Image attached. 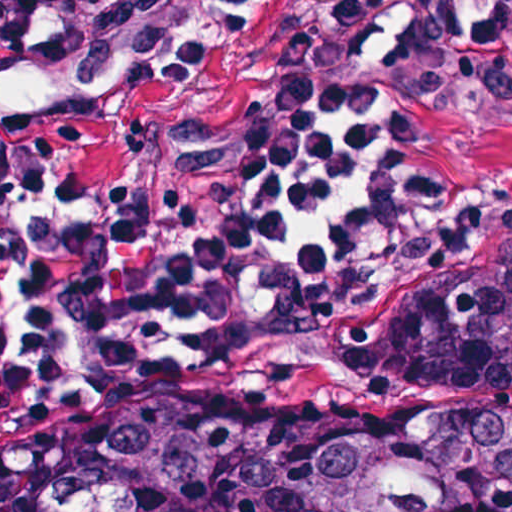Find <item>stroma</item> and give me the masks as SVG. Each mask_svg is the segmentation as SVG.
<instances>
[{
  "mask_svg": "<svg viewBox=\"0 0 512 512\" xmlns=\"http://www.w3.org/2000/svg\"><path fill=\"white\" fill-rule=\"evenodd\" d=\"M145 51L209 58L96 109L86 82L30 45L1 58L0 82L28 106L61 107L73 171L95 187L136 175L153 127L240 122L291 93L333 91L377 99L413 130L404 176L434 193L421 215L367 232L233 333L216 323L197 336H146L118 346L175 347L0 378V453L36 439L6 512H57L67 434L223 377L243 423L391 406L340 332L512 238V0H179L167 37Z\"/></svg>",
  "mask_w": 512,
  "mask_h": 512,
  "instance_id": "obj_1",
  "label": "stroma"
}]
</instances>
